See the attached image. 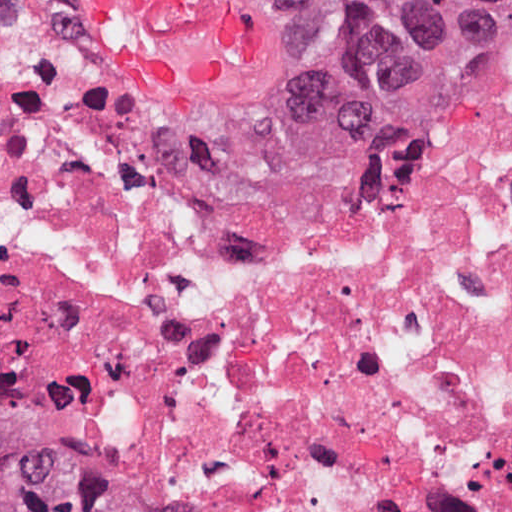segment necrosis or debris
I'll return each mask as SVG.
<instances>
[{"mask_svg": "<svg viewBox=\"0 0 512 512\" xmlns=\"http://www.w3.org/2000/svg\"><path fill=\"white\" fill-rule=\"evenodd\" d=\"M0 311L219 512H512V96L410 165L168 131L0 0Z\"/></svg>", "mask_w": 512, "mask_h": 512, "instance_id": "1", "label": "necrosis or debris"}]
</instances>
